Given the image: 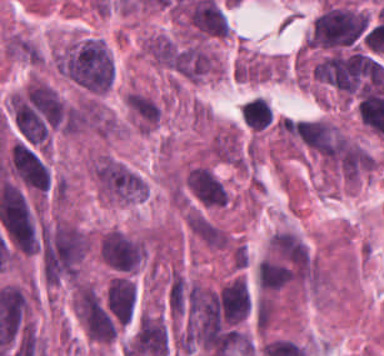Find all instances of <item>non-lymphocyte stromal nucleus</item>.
<instances>
[{
    "label": "non-lymphocyte stromal nucleus",
    "instance_id": "dd21d789",
    "mask_svg": "<svg viewBox=\"0 0 384 356\" xmlns=\"http://www.w3.org/2000/svg\"><path fill=\"white\" fill-rule=\"evenodd\" d=\"M189 232L207 248L224 250L230 245L227 231L198 210H191L186 215Z\"/></svg>",
    "mask_w": 384,
    "mask_h": 356
}]
</instances>
